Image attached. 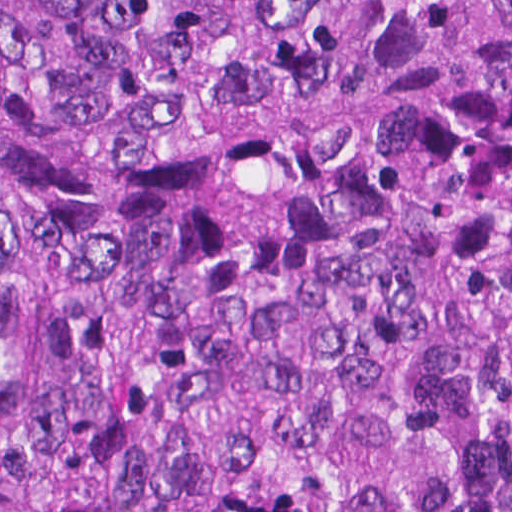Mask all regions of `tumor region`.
<instances>
[{
    "instance_id": "1",
    "label": "tumor region",
    "mask_w": 512,
    "mask_h": 512,
    "mask_svg": "<svg viewBox=\"0 0 512 512\" xmlns=\"http://www.w3.org/2000/svg\"><path fill=\"white\" fill-rule=\"evenodd\" d=\"M0 512H512V0H0Z\"/></svg>"
}]
</instances>
